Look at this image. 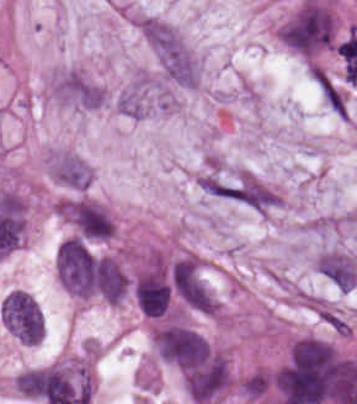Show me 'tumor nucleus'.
Instances as JSON below:
<instances>
[{
	"label": "tumor nucleus",
	"mask_w": 357,
	"mask_h": 404,
	"mask_svg": "<svg viewBox=\"0 0 357 404\" xmlns=\"http://www.w3.org/2000/svg\"><path fill=\"white\" fill-rule=\"evenodd\" d=\"M335 17L322 1L305 0L283 25L282 42L302 57H313L333 44Z\"/></svg>",
	"instance_id": "tumor-nucleus-1"
},
{
	"label": "tumor nucleus",
	"mask_w": 357,
	"mask_h": 404,
	"mask_svg": "<svg viewBox=\"0 0 357 404\" xmlns=\"http://www.w3.org/2000/svg\"><path fill=\"white\" fill-rule=\"evenodd\" d=\"M185 391L197 404H209L229 387L231 377L226 358L212 352L182 370Z\"/></svg>",
	"instance_id": "tumor-nucleus-3"
},
{
	"label": "tumor nucleus",
	"mask_w": 357,
	"mask_h": 404,
	"mask_svg": "<svg viewBox=\"0 0 357 404\" xmlns=\"http://www.w3.org/2000/svg\"><path fill=\"white\" fill-rule=\"evenodd\" d=\"M159 359L182 369H191L211 360L208 343L185 323H166L151 338Z\"/></svg>",
	"instance_id": "tumor-nucleus-2"
},
{
	"label": "tumor nucleus",
	"mask_w": 357,
	"mask_h": 404,
	"mask_svg": "<svg viewBox=\"0 0 357 404\" xmlns=\"http://www.w3.org/2000/svg\"><path fill=\"white\" fill-rule=\"evenodd\" d=\"M135 296L140 311L151 317H160L168 312L173 292L162 273L145 270L137 274Z\"/></svg>",
	"instance_id": "tumor-nucleus-5"
},
{
	"label": "tumor nucleus",
	"mask_w": 357,
	"mask_h": 404,
	"mask_svg": "<svg viewBox=\"0 0 357 404\" xmlns=\"http://www.w3.org/2000/svg\"><path fill=\"white\" fill-rule=\"evenodd\" d=\"M317 273L338 290L350 291L357 282V267L339 251H326L315 262Z\"/></svg>",
	"instance_id": "tumor-nucleus-6"
},
{
	"label": "tumor nucleus",
	"mask_w": 357,
	"mask_h": 404,
	"mask_svg": "<svg viewBox=\"0 0 357 404\" xmlns=\"http://www.w3.org/2000/svg\"><path fill=\"white\" fill-rule=\"evenodd\" d=\"M0 313L5 328L19 342L31 345L42 338V315L32 296L25 291L10 290L1 300Z\"/></svg>",
	"instance_id": "tumor-nucleus-4"
}]
</instances>
